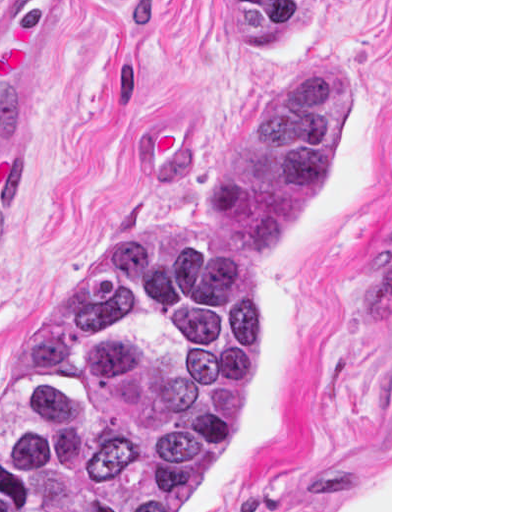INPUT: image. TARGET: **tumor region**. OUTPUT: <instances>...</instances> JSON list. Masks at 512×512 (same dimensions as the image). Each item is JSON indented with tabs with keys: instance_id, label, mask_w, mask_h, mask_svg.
<instances>
[{
	"instance_id": "1",
	"label": "tumor region",
	"mask_w": 512,
	"mask_h": 512,
	"mask_svg": "<svg viewBox=\"0 0 512 512\" xmlns=\"http://www.w3.org/2000/svg\"><path fill=\"white\" fill-rule=\"evenodd\" d=\"M219 1L251 55H273L304 4ZM355 123L354 75L294 60L181 209L64 275L0 383V512H204L271 220Z\"/></svg>"
}]
</instances>
